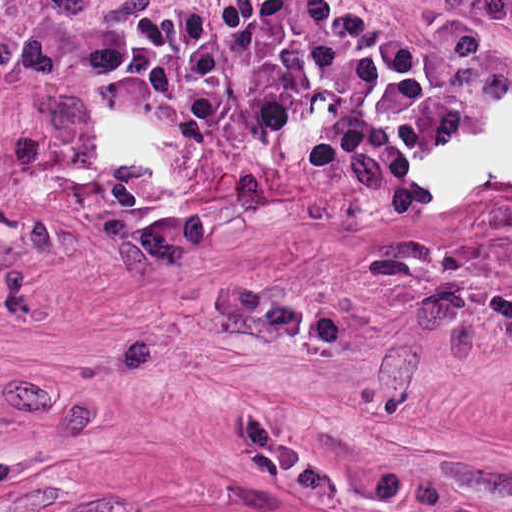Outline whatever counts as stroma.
Here are the masks:
<instances>
[{
    "label": "stroma",
    "instance_id": "obj_1",
    "mask_svg": "<svg viewBox=\"0 0 512 512\" xmlns=\"http://www.w3.org/2000/svg\"><path fill=\"white\" fill-rule=\"evenodd\" d=\"M216 0H0L17 37ZM344 0L463 128L425 205L349 212L247 92L215 148L0 58V512H512V32Z\"/></svg>",
    "mask_w": 512,
    "mask_h": 512
}]
</instances>
